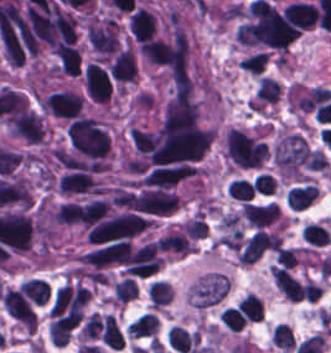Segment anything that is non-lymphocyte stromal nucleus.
Here are the masks:
<instances>
[{
	"instance_id": "obj_2",
	"label": "non-lymphocyte stromal nucleus",
	"mask_w": 331,
	"mask_h": 353,
	"mask_svg": "<svg viewBox=\"0 0 331 353\" xmlns=\"http://www.w3.org/2000/svg\"><path fill=\"white\" fill-rule=\"evenodd\" d=\"M158 328L156 314L142 312L131 320L125 330L129 338H152Z\"/></svg>"
},
{
	"instance_id": "obj_1",
	"label": "non-lymphocyte stromal nucleus",
	"mask_w": 331,
	"mask_h": 353,
	"mask_svg": "<svg viewBox=\"0 0 331 353\" xmlns=\"http://www.w3.org/2000/svg\"><path fill=\"white\" fill-rule=\"evenodd\" d=\"M228 289V276L222 272L209 271L190 283L186 298L195 308H204L221 300Z\"/></svg>"
}]
</instances>
